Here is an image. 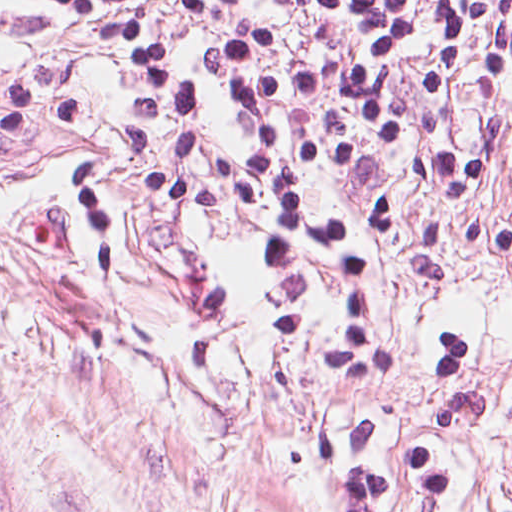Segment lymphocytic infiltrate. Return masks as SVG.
Wrapping results in <instances>:
<instances>
[{
    "label": "lymphocytic infiltrate",
    "mask_w": 512,
    "mask_h": 512,
    "mask_svg": "<svg viewBox=\"0 0 512 512\" xmlns=\"http://www.w3.org/2000/svg\"><path fill=\"white\" fill-rule=\"evenodd\" d=\"M117 52L127 92L123 154L137 192L185 253L179 354L224 360L242 341L212 259L192 245L210 201V106L163 39L154 0H38ZM214 24L201 71L244 118L240 194L278 279L314 272L340 315L345 362L393 355L373 326V285L399 215L421 214L416 278L447 284L458 252L512 253V219L472 201L498 165L500 124L469 143L464 94L512 79V0H163ZM86 96L60 75L0 83V133L79 120ZM408 158L405 183L364 204L323 207L316 177ZM87 256L114 293V225L79 168L72 200Z\"/></svg>",
    "instance_id": "1"
}]
</instances>
